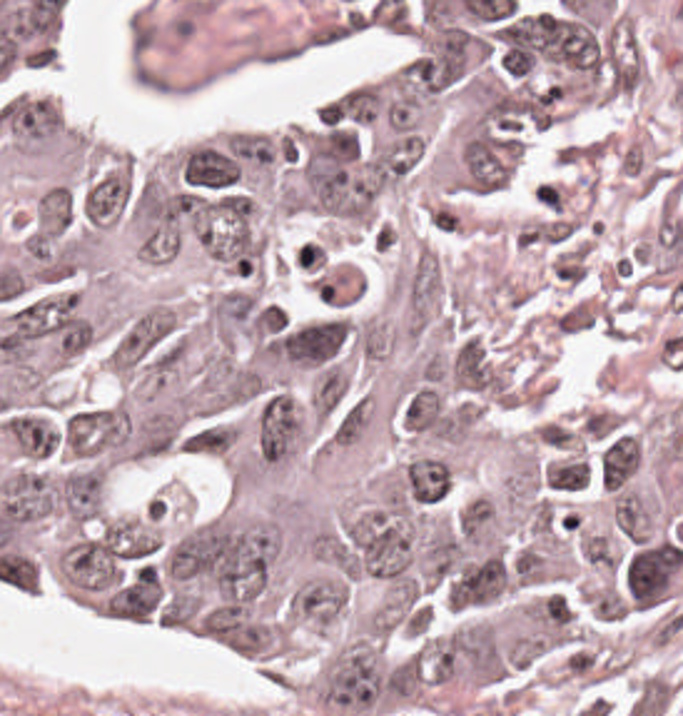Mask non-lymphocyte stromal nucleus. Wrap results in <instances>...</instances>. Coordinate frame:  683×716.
<instances>
[{"instance_id":"1","label":"non-lymphocyte stromal nucleus","mask_w":683,"mask_h":716,"mask_svg":"<svg viewBox=\"0 0 683 716\" xmlns=\"http://www.w3.org/2000/svg\"><path fill=\"white\" fill-rule=\"evenodd\" d=\"M207 325L216 340L254 342L274 323L272 301L237 286L213 291L206 305Z\"/></svg>"}]
</instances>
